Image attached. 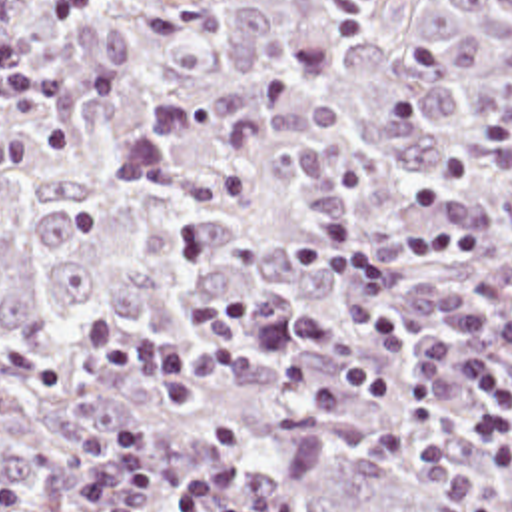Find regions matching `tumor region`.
<instances>
[{
    "label": "tumor region",
    "mask_w": 512,
    "mask_h": 512,
    "mask_svg": "<svg viewBox=\"0 0 512 512\" xmlns=\"http://www.w3.org/2000/svg\"><path fill=\"white\" fill-rule=\"evenodd\" d=\"M334 215L396 277L408 349L360 325L350 273L286 251ZM424 227L476 229V259L408 257ZM238 289L246 329L328 315L332 362L402 396L308 408L278 376L298 351L227 360L197 410L83 372L95 311L175 341ZM472 347L512 384V0H103L59 27L0 0V488L99 512L75 486L135 418L161 478L229 466L280 512H512V424L464 432Z\"/></svg>",
    "instance_id": "1"
}]
</instances>
